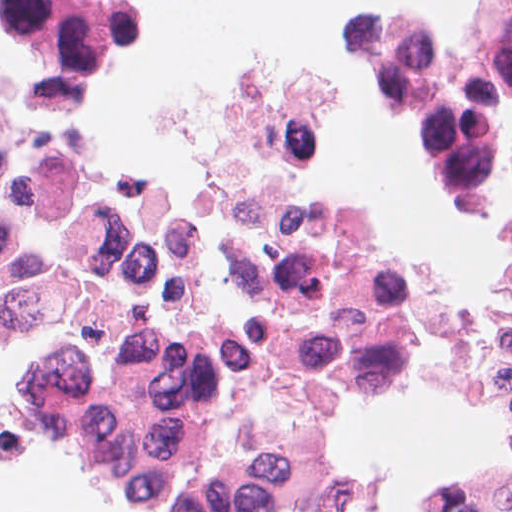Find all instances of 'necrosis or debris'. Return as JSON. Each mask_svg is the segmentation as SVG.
I'll list each match as a JSON object with an SVG mask.
<instances>
[{
    "mask_svg": "<svg viewBox=\"0 0 512 512\" xmlns=\"http://www.w3.org/2000/svg\"><path fill=\"white\" fill-rule=\"evenodd\" d=\"M137 0H0V320L36 340L124 488L154 512H340L335 421L408 389L423 345L445 382L512 428L511 290L454 302L360 204L299 197L324 79L281 64L235 89L207 148L219 212L84 140ZM364 52L454 192L479 201L512 108V0L460 30L365 20ZM512 463L433 512H504Z\"/></svg>",
    "mask_w": 512,
    "mask_h": 512,
    "instance_id": "obj_1",
    "label": "necrosis or debris"
}]
</instances>
